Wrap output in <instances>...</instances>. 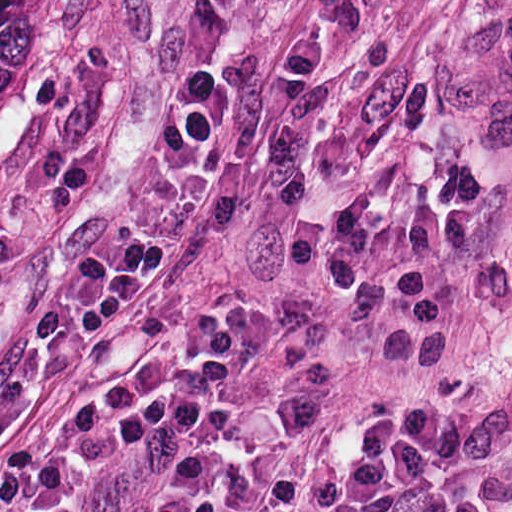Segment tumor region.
I'll use <instances>...</instances> for the list:
<instances>
[{"instance_id": "tumor-region-1", "label": "tumor region", "mask_w": 512, "mask_h": 512, "mask_svg": "<svg viewBox=\"0 0 512 512\" xmlns=\"http://www.w3.org/2000/svg\"><path fill=\"white\" fill-rule=\"evenodd\" d=\"M63 62V0H0V146L43 125Z\"/></svg>"}]
</instances>
